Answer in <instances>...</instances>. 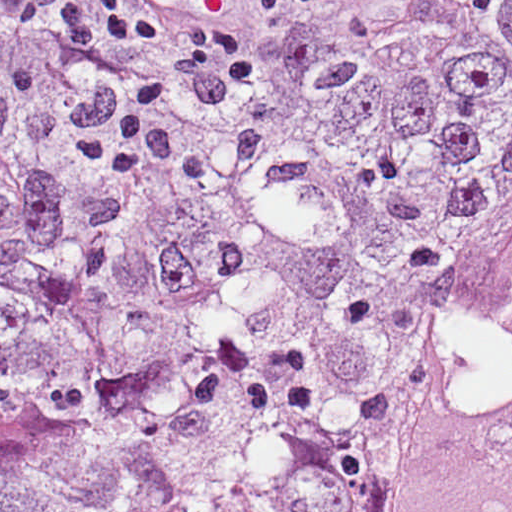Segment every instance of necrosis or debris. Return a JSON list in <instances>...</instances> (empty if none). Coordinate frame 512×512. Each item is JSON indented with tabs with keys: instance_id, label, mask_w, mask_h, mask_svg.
Returning <instances> with one entry per match:
<instances>
[{
	"instance_id": "obj_1",
	"label": "necrosis or debris",
	"mask_w": 512,
	"mask_h": 512,
	"mask_svg": "<svg viewBox=\"0 0 512 512\" xmlns=\"http://www.w3.org/2000/svg\"><path fill=\"white\" fill-rule=\"evenodd\" d=\"M389 512H512V268L465 329Z\"/></svg>"
}]
</instances>
